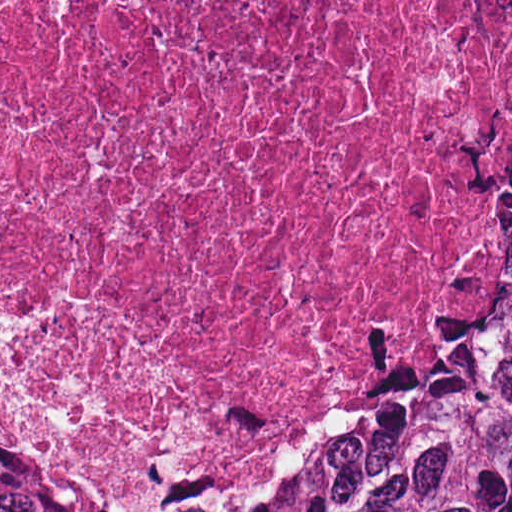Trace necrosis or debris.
<instances>
[{"label": "necrosis or debris", "mask_w": 512, "mask_h": 512, "mask_svg": "<svg viewBox=\"0 0 512 512\" xmlns=\"http://www.w3.org/2000/svg\"><path fill=\"white\" fill-rule=\"evenodd\" d=\"M511 70L512 0H0V406L128 473L292 468Z\"/></svg>", "instance_id": "1"}]
</instances>
